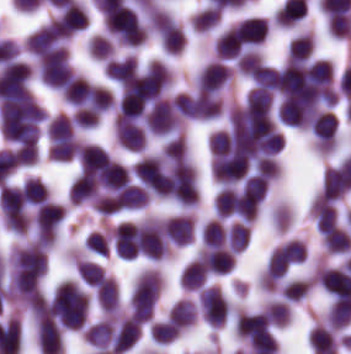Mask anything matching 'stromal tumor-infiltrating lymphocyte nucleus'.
<instances>
[{
    "label": "stromal tumor-infiltrating lymphocyte nucleus",
    "instance_id": "stromal-tumor-infiltrating-lymphocyte-nucleus-13",
    "mask_svg": "<svg viewBox=\"0 0 351 354\" xmlns=\"http://www.w3.org/2000/svg\"><path fill=\"white\" fill-rule=\"evenodd\" d=\"M97 301L107 311H114L119 304L117 284L113 276L105 275L96 285Z\"/></svg>",
    "mask_w": 351,
    "mask_h": 354
},
{
    "label": "stromal tumor-infiltrating lymphocyte nucleus",
    "instance_id": "stromal-tumor-infiltrating-lymphocyte-nucleus-14",
    "mask_svg": "<svg viewBox=\"0 0 351 354\" xmlns=\"http://www.w3.org/2000/svg\"><path fill=\"white\" fill-rule=\"evenodd\" d=\"M49 140L55 141L76 135L75 124L72 117L63 113H56L46 127Z\"/></svg>",
    "mask_w": 351,
    "mask_h": 354
},
{
    "label": "stromal tumor-infiltrating lymphocyte nucleus",
    "instance_id": "stromal-tumor-infiltrating-lymphocyte-nucleus-18",
    "mask_svg": "<svg viewBox=\"0 0 351 354\" xmlns=\"http://www.w3.org/2000/svg\"><path fill=\"white\" fill-rule=\"evenodd\" d=\"M25 201L38 205L45 201L49 191L44 183L35 176H28L22 186Z\"/></svg>",
    "mask_w": 351,
    "mask_h": 354
},
{
    "label": "stromal tumor-infiltrating lymphocyte nucleus",
    "instance_id": "stromal-tumor-infiltrating-lymphocyte-nucleus-6",
    "mask_svg": "<svg viewBox=\"0 0 351 354\" xmlns=\"http://www.w3.org/2000/svg\"><path fill=\"white\" fill-rule=\"evenodd\" d=\"M55 20L61 31L71 35L88 24V15L77 1L71 0L60 7Z\"/></svg>",
    "mask_w": 351,
    "mask_h": 354
},
{
    "label": "stromal tumor-infiltrating lymphocyte nucleus",
    "instance_id": "stromal-tumor-infiltrating-lymphocyte-nucleus-12",
    "mask_svg": "<svg viewBox=\"0 0 351 354\" xmlns=\"http://www.w3.org/2000/svg\"><path fill=\"white\" fill-rule=\"evenodd\" d=\"M79 141L77 137L52 135L49 145L51 159L69 160L77 155Z\"/></svg>",
    "mask_w": 351,
    "mask_h": 354
},
{
    "label": "stromal tumor-infiltrating lymphocyte nucleus",
    "instance_id": "stromal-tumor-infiltrating-lymphocyte-nucleus-2",
    "mask_svg": "<svg viewBox=\"0 0 351 354\" xmlns=\"http://www.w3.org/2000/svg\"><path fill=\"white\" fill-rule=\"evenodd\" d=\"M38 68L39 77L42 81L45 84L60 90L72 71L68 54L38 60Z\"/></svg>",
    "mask_w": 351,
    "mask_h": 354
},
{
    "label": "stromal tumor-infiltrating lymphocyte nucleus",
    "instance_id": "stromal-tumor-infiltrating-lymphocyte-nucleus-15",
    "mask_svg": "<svg viewBox=\"0 0 351 354\" xmlns=\"http://www.w3.org/2000/svg\"><path fill=\"white\" fill-rule=\"evenodd\" d=\"M88 87L89 83L82 76L74 74L61 89V95L72 104L82 106Z\"/></svg>",
    "mask_w": 351,
    "mask_h": 354
},
{
    "label": "stromal tumor-infiltrating lymphocyte nucleus",
    "instance_id": "stromal-tumor-infiltrating-lymphocyte-nucleus-5",
    "mask_svg": "<svg viewBox=\"0 0 351 354\" xmlns=\"http://www.w3.org/2000/svg\"><path fill=\"white\" fill-rule=\"evenodd\" d=\"M199 254L209 272L226 274L234 269L236 254L231 248L206 245Z\"/></svg>",
    "mask_w": 351,
    "mask_h": 354
},
{
    "label": "stromal tumor-infiltrating lymphocyte nucleus",
    "instance_id": "stromal-tumor-infiltrating-lymphocyte-nucleus-20",
    "mask_svg": "<svg viewBox=\"0 0 351 354\" xmlns=\"http://www.w3.org/2000/svg\"><path fill=\"white\" fill-rule=\"evenodd\" d=\"M162 155L170 159H183L188 155V144L185 136L180 132L165 141L162 145Z\"/></svg>",
    "mask_w": 351,
    "mask_h": 354
},
{
    "label": "stromal tumor-infiltrating lymphocyte nucleus",
    "instance_id": "stromal-tumor-infiltrating-lymphocyte-nucleus-21",
    "mask_svg": "<svg viewBox=\"0 0 351 354\" xmlns=\"http://www.w3.org/2000/svg\"><path fill=\"white\" fill-rule=\"evenodd\" d=\"M112 44L105 34L92 33L88 37L87 48L92 58H105L112 49Z\"/></svg>",
    "mask_w": 351,
    "mask_h": 354
},
{
    "label": "stromal tumor-infiltrating lymphocyte nucleus",
    "instance_id": "stromal-tumor-infiltrating-lymphocyte-nucleus-4",
    "mask_svg": "<svg viewBox=\"0 0 351 354\" xmlns=\"http://www.w3.org/2000/svg\"><path fill=\"white\" fill-rule=\"evenodd\" d=\"M114 125L118 143L129 149H142L145 137L140 122L124 113H117Z\"/></svg>",
    "mask_w": 351,
    "mask_h": 354
},
{
    "label": "stromal tumor-infiltrating lymphocyte nucleus",
    "instance_id": "stromal-tumor-infiltrating-lymphocyte-nucleus-19",
    "mask_svg": "<svg viewBox=\"0 0 351 354\" xmlns=\"http://www.w3.org/2000/svg\"><path fill=\"white\" fill-rule=\"evenodd\" d=\"M76 270L89 284L96 285L105 274L103 266L93 260L75 259Z\"/></svg>",
    "mask_w": 351,
    "mask_h": 354
},
{
    "label": "stromal tumor-infiltrating lymphocyte nucleus",
    "instance_id": "stromal-tumor-infiltrating-lymphocyte-nucleus-17",
    "mask_svg": "<svg viewBox=\"0 0 351 354\" xmlns=\"http://www.w3.org/2000/svg\"><path fill=\"white\" fill-rule=\"evenodd\" d=\"M227 235L223 222L218 218H210L201 230L204 246L224 244Z\"/></svg>",
    "mask_w": 351,
    "mask_h": 354
},
{
    "label": "stromal tumor-infiltrating lymphocyte nucleus",
    "instance_id": "stromal-tumor-infiltrating-lymphocyte-nucleus-7",
    "mask_svg": "<svg viewBox=\"0 0 351 354\" xmlns=\"http://www.w3.org/2000/svg\"><path fill=\"white\" fill-rule=\"evenodd\" d=\"M107 77L115 82H125L137 72V57L127 54L112 58L103 68Z\"/></svg>",
    "mask_w": 351,
    "mask_h": 354
},
{
    "label": "stromal tumor-infiltrating lymphocyte nucleus",
    "instance_id": "stromal-tumor-infiltrating-lymphocyte-nucleus-11",
    "mask_svg": "<svg viewBox=\"0 0 351 354\" xmlns=\"http://www.w3.org/2000/svg\"><path fill=\"white\" fill-rule=\"evenodd\" d=\"M167 316L182 329L195 322L197 306L190 298L181 297L171 306Z\"/></svg>",
    "mask_w": 351,
    "mask_h": 354
},
{
    "label": "stromal tumor-infiltrating lymphocyte nucleus",
    "instance_id": "stromal-tumor-infiltrating-lymphocyte-nucleus-16",
    "mask_svg": "<svg viewBox=\"0 0 351 354\" xmlns=\"http://www.w3.org/2000/svg\"><path fill=\"white\" fill-rule=\"evenodd\" d=\"M178 333V324L169 318L154 319L150 323L151 339L159 343H167Z\"/></svg>",
    "mask_w": 351,
    "mask_h": 354
},
{
    "label": "stromal tumor-infiltrating lymphocyte nucleus",
    "instance_id": "stromal-tumor-infiltrating-lymphocyte-nucleus-3",
    "mask_svg": "<svg viewBox=\"0 0 351 354\" xmlns=\"http://www.w3.org/2000/svg\"><path fill=\"white\" fill-rule=\"evenodd\" d=\"M141 327L133 316H125L113 326L111 349L117 353H124L139 338Z\"/></svg>",
    "mask_w": 351,
    "mask_h": 354
},
{
    "label": "stromal tumor-infiltrating lymphocyte nucleus",
    "instance_id": "stromal-tumor-infiltrating-lymphocyte-nucleus-1",
    "mask_svg": "<svg viewBox=\"0 0 351 354\" xmlns=\"http://www.w3.org/2000/svg\"><path fill=\"white\" fill-rule=\"evenodd\" d=\"M199 300L207 324L210 327H221L230 309L223 293L216 286L206 285L199 290Z\"/></svg>",
    "mask_w": 351,
    "mask_h": 354
},
{
    "label": "stromal tumor-infiltrating lymphocyte nucleus",
    "instance_id": "stromal-tumor-infiltrating-lymphocyte-nucleus-9",
    "mask_svg": "<svg viewBox=\"0 0 351 354\" xmlns=\"http://www.w3.org/2000/svg\"><path fill=\"white\" fill-rule=\"evenodd\" d=\"M166 235L175 244H188L194 236V218L187 215L170 217L166 221Z\"/></svg>",
    "mask_w": 351,
    "mask_h": 354
},
{
    "label": "stromal tumor-infiltrating lymphocyte nucleus",
    "instance_id": "stromal-tumor-infiltrating-lymphocyte-nucleus-8",
    "mask_svg": "<svg viewBox=\"0 0 351 354\" xmlns=\"http://www.w3.org/2000/svg\"><path fill=\"white\" fill-rule=\"evenodd\" d=\"M114 322L101 318L83 328L85 339L98 349H110Z\"/></svg>",
    "mask_w": 351,
    "mask_h": 354
},
{
    "label": "stromal tumor-infiltrating lymphocyte nucleus",
    "instance_id": "stromal-tumor-infiltrating-lymphocyte-nucleus-10",
    "mask_svg": "<svg viewBox=\"0 0 351 354\" xmlns=\"http://www.w3.org/2000/svg\"><path fill=\"white\" fill-rule=\"evenodd\" d=\"M207 279V269L200 253L183 266L181 285L188 290H197Z\"/></svg>",
    "mask_w": 351,
    "mask_h": 354
}]
</instances>
